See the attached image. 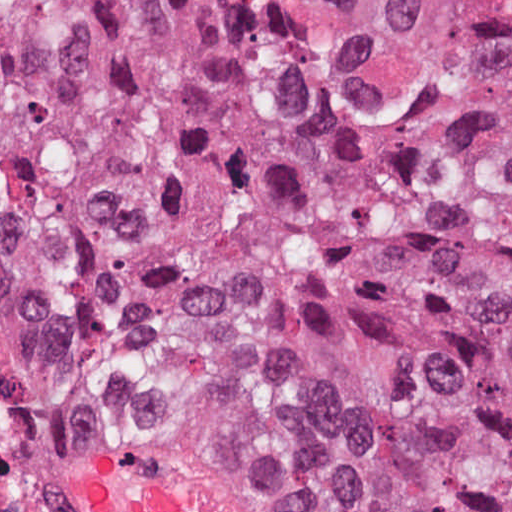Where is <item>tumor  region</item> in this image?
<instances>
[{"label":"tumor region","instance_id":"1","mask_svg":"<svg viewBox=\"0 0 512 512\" xmlns=\"http://www.w3.org/2000/svg\"><path fill=\"white\" fill-rule=\"evenodd\" d=\"M0 287L84 433L512 512V0H0Z\"/></svg>","mask_w":512,"mask_h":512}]
</instances>
